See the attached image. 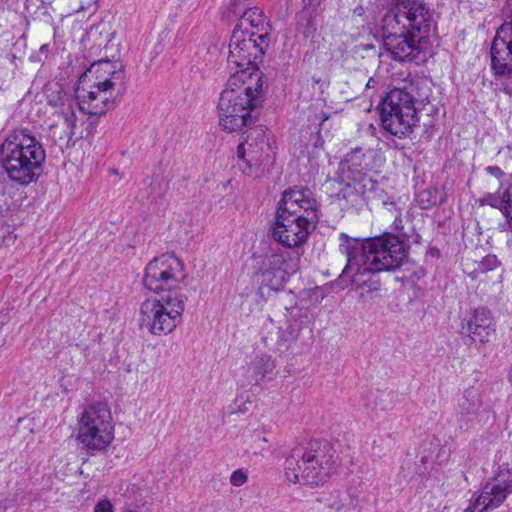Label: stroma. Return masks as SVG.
Instances as JSON below:
<instances>
[{
	"label": "stroma",
	"mask_w": 512,
	"mask_h": 512,
	"mask_svg": "<svg viewBox=\"0 0 512 512\" xmlns=\"http://www.w3.org/2000/svg\"><path fill=\"white\" fill-rule=\"evenodd\" d=\"M110 1L0 203V512H512V340L337 283L238 329L310 1Z\"/></svg>",
	"instance_id": "35a3bbf8"
}]
</instances>
